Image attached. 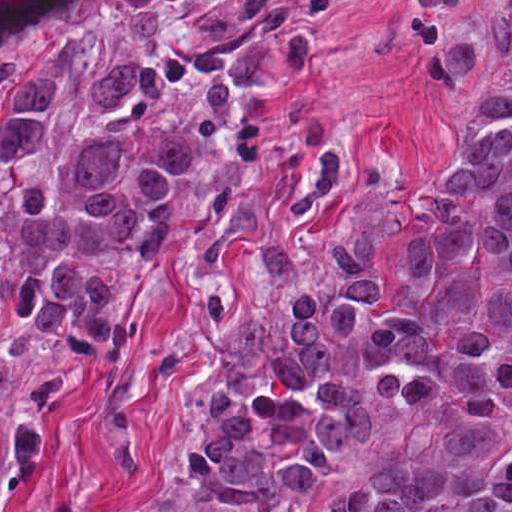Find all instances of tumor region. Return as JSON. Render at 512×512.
I'll list each match as a JSON object with an SVG mask.
<instances>
[{
    "label": "tumor region",
    "instance_id": "e687c5a6",
    "mask_svg": "<svg viewBox=\"0 0 512 512\" xmlns=\"http://www.w3.org/2000/svg\"><path fill=\"white\" fill-rule=\"evenodd\" d=\"M373 378L400 422L316 512H512V316ZM374 414L366 380L171 470L201 512H267L320 480Z\"/></svg>",
    "mask_w": 512,
    "mask_h": 512
}]
</instances>
